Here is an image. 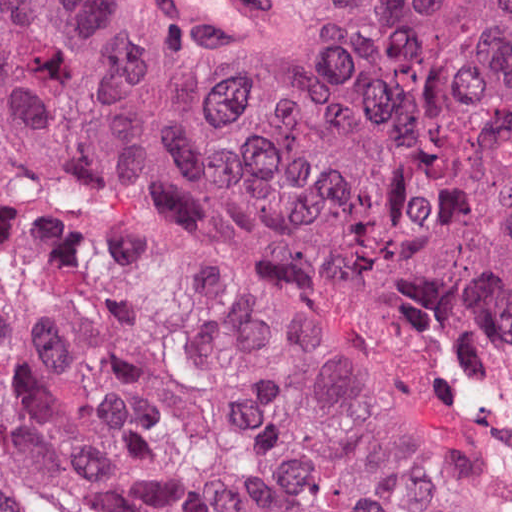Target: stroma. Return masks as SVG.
Instances as JSON below:
<instances>
[{
  "instance_id": "35a3bbf8",
  "label": "stroma",
  "mask_w": 512,
  "mask_h": 512,
  "mask_svg": "<svg viewBox=\"0 0 512 512\" xmlns=\"http://www.w3.org/2000/svg\"><path fill=\"white\" fill-rule=\"evenodd\" d=\"M266 1L277 12V22L267 31L247 39H206L222 56L240 93L269 68L273 48L288 37L278 1ZM374 346L406 349L454 392L464 511L512 512V337L472 315H405L391 332L354 326L343 349Z\"/></svg>"
}]
</instances>
